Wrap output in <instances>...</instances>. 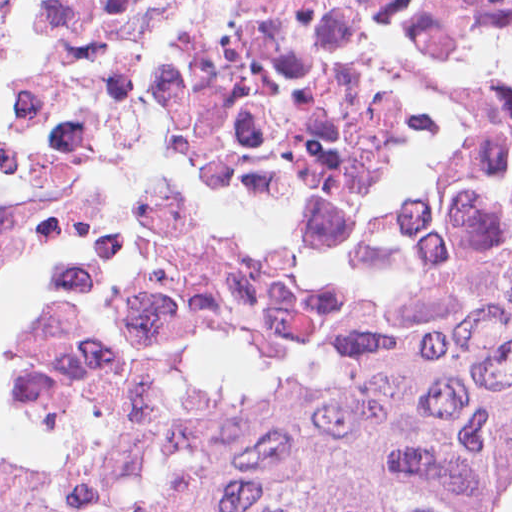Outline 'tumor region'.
<instances>
[{"label":"tumor region","mask_w":512,"mask_h":512,"mask_svg":"<svg viewBox=\"0 0 512 512\" xmlns=\"http://www.w3.org/2000/svg\"><path fill=\"white\" fill-rule=\"evenodd\" d=\"M512 282L396 346L212 362L137 463L0 421V512H504Z\"/></svg>","instance_id":"obj_1"}]
</instances>
